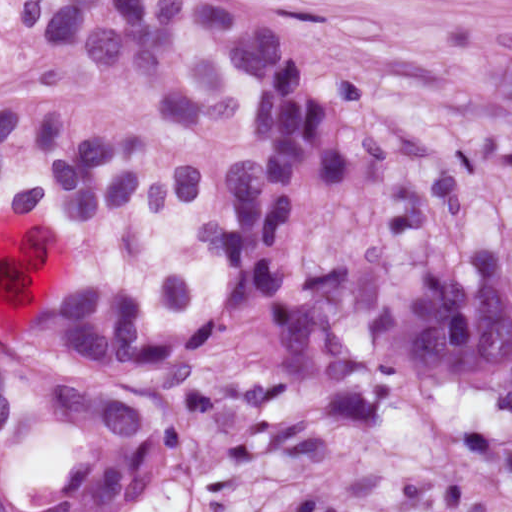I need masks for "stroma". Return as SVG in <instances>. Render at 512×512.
I'll return each mask as SVG.
<instances>
[{
  "label": "stroma",
  "mask_w": 512,
  "mask_h": 512,
  "mask_svg": "<svg viewBox=\"0 0 512 512\" xmlns=\"http://www.w3.org/2000/svg\"><path fill=\"white\" fill-rule=\"evenodd\" d=\"M352 1L512 358V15Z\"/></svg>",
  "instance_id": "stroma-1"
}]
</instances>
